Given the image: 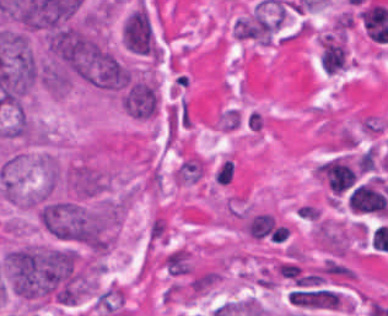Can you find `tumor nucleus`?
Returning a JSON list of instances; mask_svg holds the SVG:
<instances>
[{"mask_svg":"<svg viewBox=\"0 0 388 316\" xmlns=\"http://www.w3.org/2000/svg\"><path fill=\"white\" fill-rule=\"evenodd\" d=\"M38 225L50 237L92 246L96 233V212L90 203L49 197L36 209Z\"/></svg>","mask_w":388,"mask_h":316,"instance_id":"obj_2","label":"tumor nucleus"},{"mask_svg":"<svg viewBox=\"0 0 388 316\" xmlns=\"http://www.w3.org/2000/svg\"><path fill=\"white\" fill-rule=\"evenodd\" d=\"M121 43L127 51L159 62L161 50L154 24L146 7L140 5L124 16Z\"/></svg>","mask_w":388,"mask_h":316,"instance_id":"obj_5","label":"tumor nucleus"},{"mask_svg":"<svg viewBox=\"0 0 388 316\" xmlns=\"http://www.w3.org/2000/svg\"><path fill=\"white\" fill-rule=\"evenodd\" d=\"M118 100L129 117L149 120L160 109V89L152 69H139L124 84Z\"/></svg>","mask_w":388,"mask_h":316,"instance_id":"obj_3","label":"tumor nucleus"},{"mask_svg":"<svg viewBox=\"0 0 388 316\" xmlns=\"http://www.w3.org/2000/svg\"><path fill=\"white\" fill-rule=\"evenodd\" d=\"M62 179L69 195L86 200L106 192L112 177L102 166L81 155L62 170Z\"/></svg>","mask_w":388,"mask_h":316,"instance_id":"obj_4","label":"tumor nucleus"},{"mask_svg":"<svg viewBox=\"0 0 388 316\" xmlns=\"http://www.w3.org/2000/svg\"><path fill=\"white\" fill-rule=\"evenodd\" d=\"M10 289L33 302L71 304L79 292L76 250L22 245L1 258Z\"/></svg>","mask_w":388,"mask_h":316,"instance_id":"obj_1","label":"tumor nucleus"}]
</instances>
